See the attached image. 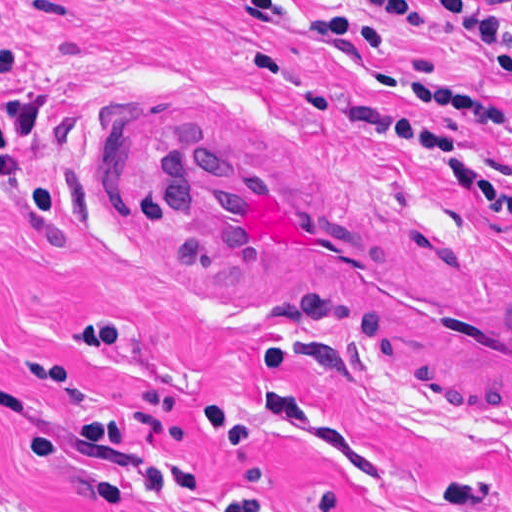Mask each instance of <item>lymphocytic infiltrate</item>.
Segmentation results:
<instances>
[{
  "label": "lymphocytic infiltrate",
  "mask_w": 512,
  "mask_h": 512,
  "mask_svg": "<svg viewBox=\"0 0 512 512\" xmlns=\"http://www.w3.org/2000/svg\"><path fill=\"white\" fill-rule=\"evenodd\" d=\"M216 1L264 22L283 40L302 49L350 44L378 53L394 51L392 37L363 19L323 16L284 0ZM360 1L375 10L427 26L444 38L463 39L486 60L493 75L512 82V0H423L445 14L469 17L480 27L445 21L403 0ZM405 94L408 101L417 105H436L466 115L472 126L466 131L433 129L364 106L347 107L334 116L342 120H381L417 132L472 188L512 213V189L491 167H468L467 163L471 150L505 128L508 112L437 86H409ZM0 512L45 511L35 499L0 477Z\"/></svg>",
  "instance_id": "lymphocytic-infiltrate-1"
}]
</instances>
